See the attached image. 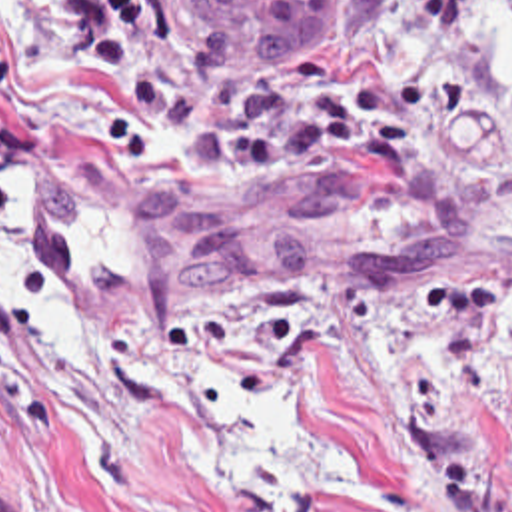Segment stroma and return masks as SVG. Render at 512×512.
Wrapping results in <instances>:
<instances>
[{"mask_svg":"<svg viewBox=\"0 0 512 512\" xmlns=\"http://www.w3.org/2000/svg\"><path fill=\"white\" fill-rule=\"evenodd\" d=\"M512 0L0 8V512H512Z\"/></svg>","mask_w":512,"mask_h":512,"instance_id":"stroma-1","label":"stroma"}]
</instances>
